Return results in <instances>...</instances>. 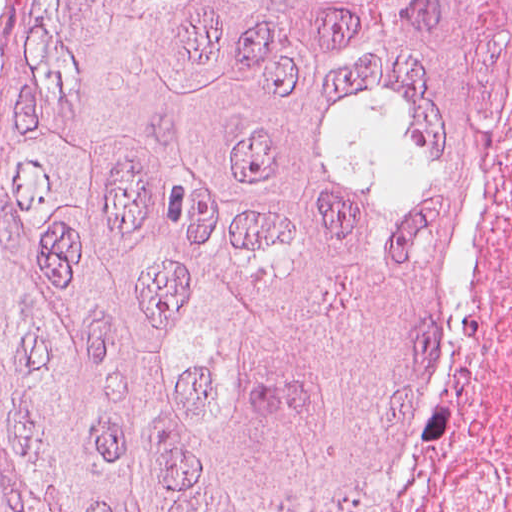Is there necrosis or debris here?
<instances>
[{"instance_id": "4bbe7bcc", "label": "necrosis or debris", "mask_w": 512, "mask_h": 512, "mask_svg": "<svg viewBox=\"0 0 512 512\" xmlns=\"http://www.w3.org/2000/svg\"><path fill=\"white\" fill-rule=\"evenodd\" d=\"M510 201L471 323L450 355L425 447L383 512H512Z\"/></svg>"}]
</instances>
